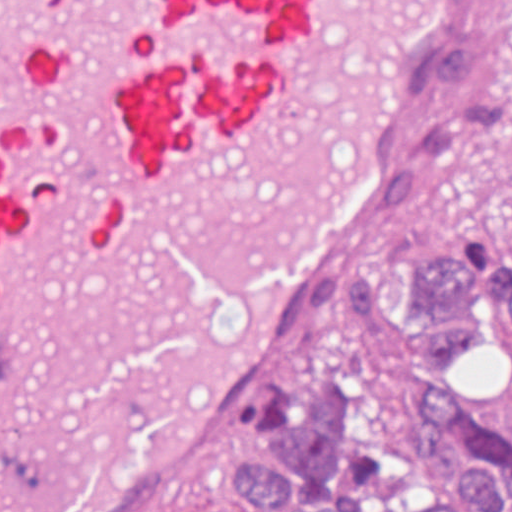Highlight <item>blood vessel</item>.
I'll return each mask as SVG.
<instances>
[{
	"instance_id": "8fb6f2fc",
	"label": "blood vessel",
	"mask_w": 512,
	"mask_h": 512,
	"mask_svg": "<svg viewBox=\"0 0 512 512\" xmlns=\"http://www.w3.org/2000/svg\"><path fill=\"white\" fill-rule=\"evenodd\" d=\"M466 0H0V512H152L408 208Z\"/></svg>"
}]
</instances>
